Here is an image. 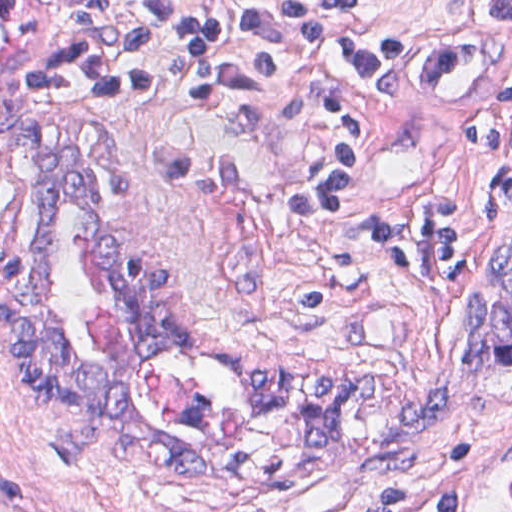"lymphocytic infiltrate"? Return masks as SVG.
<instances>
[{
	"mask_svg": "<svg viewBox=\"0 0 512 512\" xmlns=\"http://www.w3.org/2000/svg\"><path fill=\"white\" fill-rule=\"evenodd\" d=\"M62 54L28 90L65 104H97L153 90L154 50L165 58L184 100L257 97L275 90V43L306 56L339 113V139L325 159L288 189L296 215H333L360 195L379 163V138L338 83L382 84L401 65L400 29L361 10L369 0H56ZM490 16L512 23V0H490ZM41 94V95H39ZM494 152L496 219H512V82L489 93L469 130ZM383 261L432 281L472 271V227L458 197L433 191L409 206L385 208L376 222ZM431 273L437 277L434 279ZM1 512H62L36 500L1 466ZM367 512H459L454 485L380 487Z\"/></svg>",
	"mask_w": 512,
	"mask_h": 512,
	"instance_id": "lymphocytic-infiltrate-1",
	"label": "lymphocytic infiltrate"
}]
</instances>
